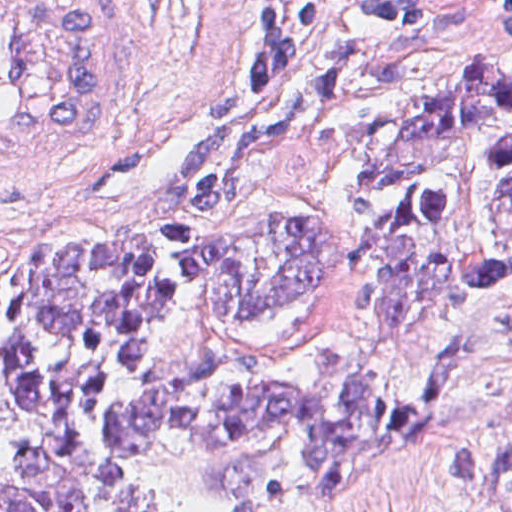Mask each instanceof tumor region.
<instances>
[{"mask_svg": "<svg viewBox=\"0 0 512 512\" xmlns=\"http://www.w3.org/2000/svg\"><path fill=\"white\" fill-rule=\"evenodd\" d=\"M289 140L353 163L361 332L400 337L512 279V78L469 59L345 61L187 143L161 236L45 237L31 265L0 262V359L25 418L0 512H271L429 440L427 409L377 392L350 340L300 377L238 345L250 320L345 278L349 236L320 215L206 236ZM415 365L483 511L512 512V287Z\"/></svg>", "mask_w": 512, "mask_h": 512, "instance_id": "tumor-region-1", "label": "tumor region"}]
</instances>
